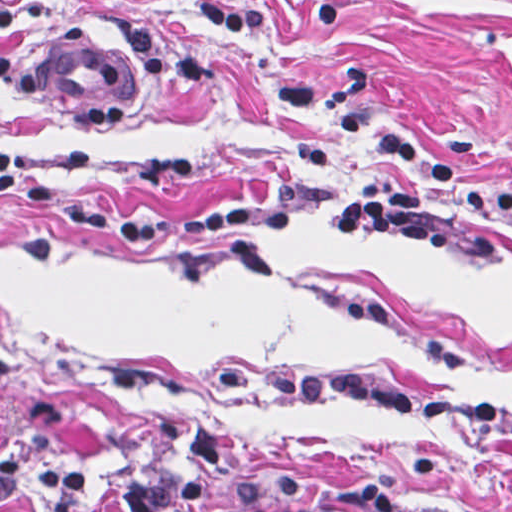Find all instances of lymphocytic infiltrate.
I'll list each match as a JSON object with an SVG mask.
<instances>
[{
  "label": "lymphocytic infiltrate",
  "mask_w": 512,
  "mask_h": 512,
  "mask_svg": "<svg viewBox=\"0 0 512 512\" xmlns=\"http://www.w3.org/2000/svg\"><path fill=\"white\" fill-rule=\"evenodd\" d=\"M12 0H0V29L17 24ZM213 27L225 33H252L268 25L270 9L260 1L207 0L201 3ZM316 31H332L343 19L342 0H306ZM371 155L407 167L404 175L364 185L324 220L333 241L403 243L434 253L455 252L463 230L439 215L431 193L460 175L453 156L415 140L387 134ZM0 185L44 217L110 240L164 246L247 226L275 233L297 231L299 209L264 201H234L180 220H135L70 203L43 177L30 171L18 151L0 144ZM462 206L512 218V192L460 194ZM223 389L277 396L296 403H363L402 420L448 418L512 434V406H472L450 397H420L364 370H224L206 374ZM8 362L0 356V398ZM165 433L182 445L172 461L154 462L111 489L89 485L73 460L0 462V509L19 495L40 497L47 512H229L227 487L235 466L219 428L202 420H168Z\"/></svg>",
  "instance_id": "1"
}]
</instances>
